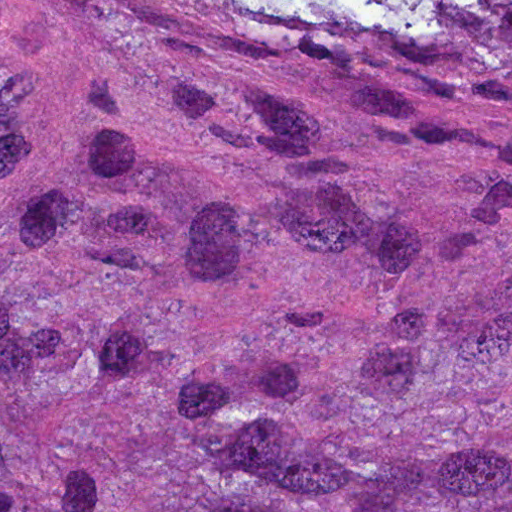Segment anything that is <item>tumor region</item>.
I'll return each mask as SVG.
<instances>
[{"label":"tumor region","instance_id":"1","mask_svg":"<svg viewBox=\"0 0 512 512\" xmlns=\"http://www.w3.org/2000/svg\"><path fill=\"white\" fill-rule=\"evenodd\" d=\"M0 512H512V0H0Z\"/></svg>","mask_w":512,"mask_h":512}]
</instances>
